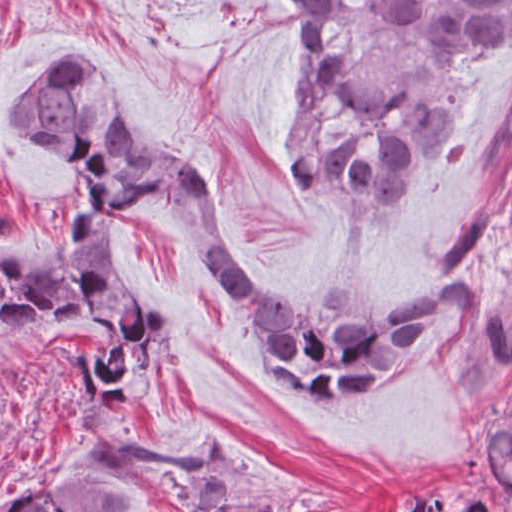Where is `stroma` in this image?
Masks as SVG:
<instances>
[{
	"label": "stroma",
	"mask_w": 512,
	"mask_h": 512,
	"mask_svg": "<svg viewBox=\"0 0 512 512\" xmlns=\"http://www.w3.org/2000/svg\"><path fill=\"white\" fill-rule=\"evenodd\" d=\"M366 92L469 108L453 173L413 206L367 222L294 199L286 180L287 36L265 0H0V248L30 257L76 193L46 146L6 124L57 61L102 68L132 132L203 169L231 248L271 295L312 304L337 272L391 302L475 279L480 313L403 376L345 400L286 386L241 309L151 195L117 214L134 304L162 314L132 389L138 440L183 446L226 430L286 489L290 512H391L417 492L512 512L480 465L512 376H486L482 311L512 304V37L460 65L398 46L380 0H332ZM78 351L110 360L89 317L20 321L0 311V512L74 450L65 423L87 387Z\"/></svg>",
	"instance_id": "obj_1"
}]
</instances>
